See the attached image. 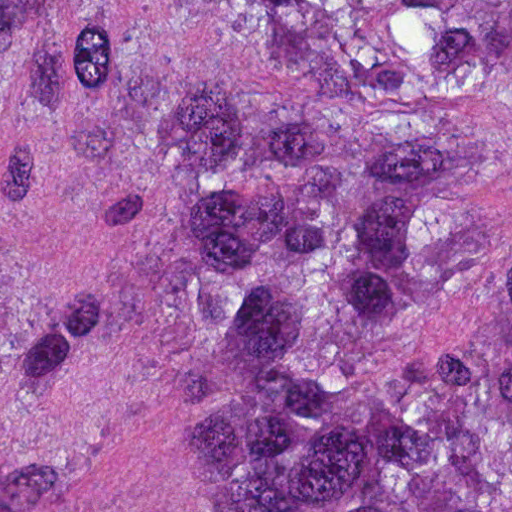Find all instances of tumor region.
Instances as JSON below:
<instances>
[{"label": "tumor region", "instance_id": "e687c5a6", "mask_svg": "<svg viewBox=\"0 0 512 512\" xmlns=\"http://www.w3.org/2000/svg\"><path fill=\"white\" fill-rule=\"evenodd\" d=\"M0 512H512V0H0Z\"/></svg>", "mask_w": 512, "mask_h": 512}]
</instances>
